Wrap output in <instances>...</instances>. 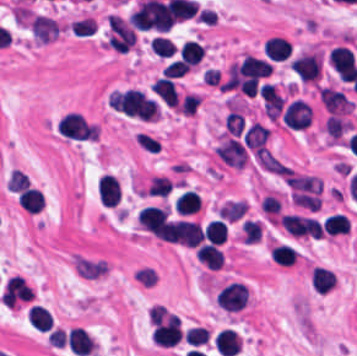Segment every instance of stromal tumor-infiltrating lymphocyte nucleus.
Instances as JSON below:
<instances>
[{
	"mask_svg": "<svg viewBox=\"0 0 357 356\" xmlns=\"http://www.w3.org/2000/svg\"><path fill=\"white\" fill-rule=\"evenodd\" d=\"M309 283L313 291L326 293L335 284V274L320 266H313L309 272Z\"/></svg>",
	"mask_w": 357,
	"mask_h": 356,
	"instance_id": "4c9ddf68",
	"label": "stromal tumor-infiltrating lymphocyte nucleus"
},
{
	"mask_svg": "<svg viewBox=\"0 0 357 356\" xmlns=\"http://www.w3.org/2000/svg\"><path fill=\"white\" fill-rule=\"evenodd\" d=\"M218 305L227 311H238L245 306L248 296L245 283L229 282L220 289L216 297Z\"/></svg>",
	"mask_w": 357,
	"mask_h": 356,
	"instance_id": "52c7bb5b",
	"label": "stromal tumor-infiltrating lymphocyte nucleus"
},
{
	"mask_svg": "<svg viewBox=\"0 0 357 356\" xmlns=\"http://www.w3.org/2000/svg\"><path fill=\"white\" fill-rule=\"evenodd\" d=\"M29 326L35 331H49L51 328L47 311L39 305H32L27 310Z\"/></svg>",
	"mask_w": 357,
	"mask_h": 356,
	"instance_id": "cac63f63",
	"label": "stromal tumor-infiltrating lymphocyte nucleus"
},
{
	"mask_svg": "<svg viewBox=\"0 0 357 356\" xmlns=\"http://www.w3.org/2000/svg\"><path fill=\"white\" fill-rule=\"evenodd\" d=\"M205 240L207 242L222 244L226 237V227L221 219H213L204 225Z\"/></svg>",
	"mask_w": 357,
	"mask_h": 356,
	"instance_id": "c26a33f6",
	"label": "stromal tumor-infiltrating lymphocyte nucleus"
},
{
	"mask_svg": "<svg viewBox=\"0 0 357 356\" xmlns=\"http://www.w3.org/2000/svg\"><path fill=\"white\" fill-rule=\"evenodd\" d=\"M97 198L99 203L114 206L119 203L120 186L115 176L103 174L97 183Z\"/></svg>",
	"mask_w": 357,
	"mask_h": 356,
	"instance_id": "4803ca6d",
	"label": "stromal tumor-infiltrating lymphocyte nucleus"
},
{
	"mask_svg": "<svg viewBox=\"0 0 357 356\" xmlns=\"http://www.w3.org/2000/svg\"><path fill=\"white\" fill-rule=\"evenodd\" d=\"M234 68L239 77L259 79L265 78L272 67L269 62L260 57L245 55Z\"/></svg>",
	"mask_w": 357,
	"mask_h": 356,
	"instance_id": "4f13568d",
	"label": "stromal tumor-infiltrating lymphocyte nucleus"
},
{
	"mask_svg": "<svg viewBox=\"0 0 357 356\" xmlns=\"http://www.w3.org/2000/svg\"><path fill=\"white\" fill-rule=\"evenodd\" d=\"M328 62L339 79L353 80L357 66L351 51L342 45H335L329 50Z\"/></svg>",
	"mask_w": 357,
	"mask_h": 356,
	"instance_id": "bc302bb0",
	"label": "stromal tumor-infiltrating lymphocyte nucleus"
},
{
	"mask_svg": "<svg viewBox=\"0 0 357 356\" xmlns=\"http://www.w3.org/2000/svg\"><path fill=\"white\" fill-rule=\"evenodd\" d=\"M318 97L330 115H341L352 108L350 100L337 89L320 87Z\"/></svg>",
	"mask_w": 357,
	"mask_h": 356,
	"instance_id": "9ea309e8",
	"label": "stromal tumor-infiltrating lymphocyte nucleus"
},
{
	"mask_svg": "<svg viewBox=\"0 0 357 356\" xmlns=\"http://www.w3.org/2000/svg\"><path fill=\"white\" fill-rule=\"evenodd\" d=\"M58 129L67 139H87L91 126L77 113L67 112L59 121Z\"/></svg>",
	"mask_w": 357,
	"mask_h": 356,
	"instance_id": "abfb95fc",
	"label": "stromal tumor-infiltrating lymphocyte nucleus"
},
{
	"mask_svg": "<svg viewBox=\"0 0 357 356\" xmlns=\"http://www.w3.org/2000/svg\"><path fill=\"white\" fill-rule=\"evenodd\" d=\"M150 47L153 52L162 57H172L175 53V45L169 37L156 35L150 41Z\"/></svg>",
	"mask_w": 357,
	"mask_h": 356,
	"instance_id": "3e0999b9",
	"label": "stromal tumor-infiltrating lymphocyte nucleus"
},
{
	"mask_svg": "<svg viewBox=\"0 0 357 356\" xmlns=\"http://www.w3.org/2000/svg\"><path fill=\"white\" fill-rule=\"evenodd\" d=\"M65 340L71 353L88 355L94 350L93 338L79 327H72L66 334Z\"/></svg>",
	"mask_w": 357,
	"mask_h": 356,
	"instance_id": "2a367800",
	"label": "stromal tumor-infiltrating lymphocyte nucleus"
},
{
	"mask_svg": "<svg viewBox=\"0 0 357 356\" xmlns=\"http://www.w3.org/2000/svg\"><path fill=\"white\" fill-rule=\"evenodd\" d=\"M195 256L207 267L217 268L224 262V256L218 246L202 243L195 249Z\"/></svg>",
	"mask_w": 357,
	"mask_h": 356,
	"instance_id": "3c572f05",
	"label": "stromal tumor-infiltrating lymphocyte nucleus"
},
{
	"mask_svg": "<svg viewBox=\"0 0 357 356\" xmlns=\"http://www.w3.org/2000/svg\"><path fill=\"white\" fill-rule=\"evenodd\" d=\"M215 347L223 356H234L240 348V337L230 329H223L215 336Z\"/></svg>",
	"mask_w": 357,
	"mask_h": 356,
	"instance_id": "2761f720",
	"label": "stromal tumor-infiltrating lymphocyte nucleus"
},
{
	"mask_svg": "<svg viewBox=\"0 0 357 356\" xmlns=\"http://www.w3.org/2000/svg\"><path fill=\"white\" fill-rule=\"evenodd\" d=\"M269 254L272 261L282 266H291L297 255L292 248L284 244H277L270 247Z\"/></svg>",
	"mask_w": 357,
	"mask_h": 356,
	"instance_id": "7eef579d",
	"label": "stromal tumor-infiltrating lymphocyte nucleus"
},
{
	"mask_svg": "<svg viewBox=\"0 0 357 356\" xmlns=\"http://www.w3.org/2000/svg\"><path fill=\"white\" fill-rule=\"evenodd\" d=\"M200 204V198L195 191L185 190L174 198V212L180 215H187L194 212Z\"/></svg>",
	"mask_w": 357,
	"mask_h": 356,
	"instance_id": "e9af9c67",
	"label": "stromal tumor-infiltrating lymphocyte nucleus"
},
{
	"mask_svg": "<svg viewBox=\"0 0 357 356\" xmlns=\"http://www.w3.org/2000/svg\"><path fill=\"white\" fill-rule=\"evenodd\" d=\"M291 47L283 37L271 36L263 46V53L274 61L286 59Z\"/></svg>",
	"mask_w": 357,
	"mask_h": 356,
	"instance_id": "42bb06b2",
	"label": "stromal tumor-infiltrating lymphocyte nucleus"
},
{
	"mask_svg": "<svg viewBox=\"0 0 357 356\" xmlns=\"http://www.w3.org/2000/svg\"><path fill=\"white\" fill-rule=\"evenodd\" d=\"M349 228L350 226L346 216L336 212L328 214L322 223V231L333 236L346 234Z\"/></svg>",
	"mask_w": 357,
	"mask_h": 356,
	"instance_id": "782c7336",
	"label": "stromal tumor-infiltrating lymphocyte nucleus"
},
{
	"mask_svg": "<svg viewBox=\"0 0 357 356\" xmlns=\"http://www.w3.org/2000/svg\"><path fill=\"white\" fill-rule=\"evenodd\" d=\"M351 127L350 123L343 117L329 115L324 123L325 133L330 139H338Z\"/></svg>",
	"mask_w": 357,
	"mask_h": 356,
	"instance_id": "2e467ee5",
	"label": "stromal tumor-infiltrating lymphocyte nucleus"
},
{
	"mask_svg": "<svg viewBox=\"0 0 357 356\" xmlns=\"http://www.w3.org/2000/svg\"><path fill=\"white\" fill-rule=\"evenodd\" d=\"M205 51L199 42L185 40L178 49V56L186 67H194L203 57Z\"/></svg>",
	"mask_w": 357,
	"mask_h": 356,
	"instance_id": "9e4306bb",
	"label": "stromal tumor-infiltrating lymphocyte nucleus"
},
{
	"mask_svg": "<svg viewBox=\"0 0 357 356\" xmlns=\"http://www.w3.org/2000/svg\"><path fill=\"white\" fill-rule=\"evenodd\" d=\"M167 217V208L148 204L141 208L137 224L156 234L167 221Z\"/></svg>",
	"mask_w": 357,
	"mask_h": 356,
	"instance_id": "f3e2335f",
	"label": "stromal tumor-infiltrating lymphocyte nucleus"
},
{
	"mask_svg": "<svg viewBox=\"0 0 357 356\" xmlns=\"http://www.w3.org/2000/svg\"><path fill=\"white\" fill-rule=\"evenodd\" d=\"M183 337L186 341L193 345L198 346L204 342H207L208 336L203 327L193 326L187 330H185Z\"/></svg>",
	"mask_w": 357,
	"mask_h": 356,
	"instance_id": "b6af03f8",
	"label": "stromal tumor-infiltrating lymphocyte nucleus"
},
{
	"mask_svg": "<svg viewBox=\"0 0 357 356\" xmlns=\"http://www.w3.org/2000/svg\"><path fill=\"white\" fill-rule=\"evenodd\" d=\"M151 91L157 98L168 106H174L178 95L170 77H157L151 84Z\"/></svg>",
	"mask_w": 357,
	"mask_h": 356,
	"instance_id": "4245b91a",
	"label": "stromal tumor-infiltrating lymphocyte nucleus"
},
{
	"mask_svg": "<svg viewBox=\"0 0 357 356\" xmlns=\"http://www.w3.org/2000/svg\"><path fill=\"white\" fill-rule=\"evenodd\" d=\"M312 111L305 100L292 99L285 107L281 119L284 124L293 129L308 127Z\"/></svg>",
	"mask_w": 357,
	"mask_h": 356,
	"instance_id": "3290ff9b",
	"label": "stromal tumor-infiltrating lymphocyte nucleus"
},
{
	"mask_svg": "<svg viewBox=\"0 0 357 356\" xmlns=\"http://www.w3.org/2000/svg\"><path fill=\"white\" fill-rule=\"evenodd\" d=\"M29 186V179L23 171L19 169H12L6 180L7 191H20Z\"/></svg>",
	"mask_w": 357,
	"mask_h": 356,
	"instance_id": "a0a3295f",
	"label": "stromal tumor-infiltrating lymphocyte nucleus"
},
{
	"mask_svg": "<svg viewBox=\"0 0 357 356\" xmlns=\"http://www.w3.org/2000/svg\"><path fill=\"white\" fill-rule=\"evenodd\" d=\"M17 202L27 213L34 214L42 208L44 197L41 191L29 186L21 192Z\"/></svg>",
	"mask_w": 357,
	"mask_h": 356,
	"instance_id": "04cf8593",
	"label": "stromal tumor-infiltrating lymphocyte nucleus"
}]
</instances>
